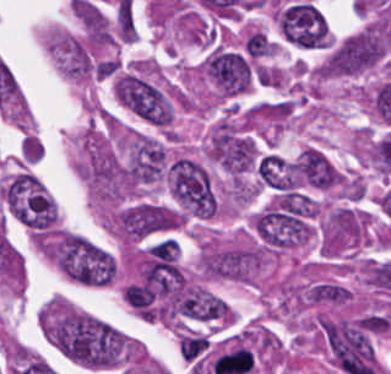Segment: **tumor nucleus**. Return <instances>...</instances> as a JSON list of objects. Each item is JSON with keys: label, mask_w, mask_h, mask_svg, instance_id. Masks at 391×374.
Masks as SVG:
<instances>
[{"label": "tumor nucleus", "mask_w": 391, "mask_h": 374, "mask_svg": "<svg viewBox=\"0 0 391 374\" xmlns=\"http://www.w3.org/2000/svg\"><path fill=\"white\" fill-rule=\"evenodd\" d=\"M274 19L280 40L291 46H329L330 36L325 17L311 1L283 3L277 8Z\"/></svg>", "instance_id": "obj_7"}, {"label": "tumor nucleus", "mask_w": 391, "mask_h": 374, "mask_svg": "<svg viewBox=\"0 0 391 374\" xmlns=\"http://www.w3.org/2000/svg\"><path fill=\"white\" fill-rule=\"evenodd\" d=\"M106 224L119 238L129 241L174 229L180 224V215L172 207L140 199L119 207Z\"/></svg>", "instance_id": "obj_5"}, {"label": "tumor nucleus", "mask_w": 391, "mask_h": 374, "mask_svg": "<svg viewBox=\"0 0 391 374\" xmlns=\"http://www.w3.org/2000/svg\"><path fill=\"white\" fill-rule=\"evenodd\" d=\"M205 153L225 172L241 175L258 161L259 147L248 132L221 117L207 138Z\"/></svg>", "instance_id": "obj_6"}, {"label": "tumor nucleus", "mask_w": 391, "mask_h": 374, "mask_svg": "<svg viewBox=\"0 0 391 374\" xmlns=\"http://www.w3.org/2000/svg\"><path fill=\"white\" fill-rule=\"evenodd\" d=\"M0 197L7 213L26 229L36 232L54 230V199L31 172L19 171L0 181Z\"/></svg>", "instance_id": "obj_1"}, {"label": "tumor nucleus", "mask_w": 391, "mask_h": 374, "mask_svg": "<svg viewBox=\"0 0 391 374\" xmlns=\"http://www.w3.org/2000/svg\"><path fill=\"white\" fill-rule=\"evenodd\" d=\"M391 42L389 25L371 24L332 43L326 54L324 73H362L377 65Z\"/></svg>", "instance_id": "obj_2"}, {"label": "tumor nucleus", "mask_w": 391, "mask_h": 374, "mask_svg": "<svg viewBox=\"0 0 391 374\" xmlns=\"http://www.w3.org/2000/svg\"><path fill=\"white\" fill-rule=\"evenodd\" d=\"M276 43L274 40L266 36L261 31H254L245 40V49L249 56L262 57L269 56L276 51Z\"/></svg>", "instance_id": "obj_8"}, {"label": "tumor nucleus", "mask_w": 391, "mask_h": 374, "mask_svg": "<svg viewBox=\"0 0 391 374\" xmlns=\"http://www.w3.org/2000/svg\"><path fill=\"white\" fill-rule=\"evenodd\" d=\"M198 73L220 97H233L249 88L257 76L254 59L237 48L211 45Z\"/></svg>", "instance_id": "obj_4"}, {"label": "tumor nucleus", "mask_w": 391, "mask_h": 374, "mask_svg": "<svg viewBox=\"0 0 391 374\" xmlns=\"http://www.w3.org/2000/svg\"><path fill=\"white\" fill-rule=\"evenodd\" d=\"M166 177L171 196L183 214L207 218L217 212V195L206 166L177 155L168 163Z\"/></svg>", "instance_id": "obj_3"}]
</instances>
